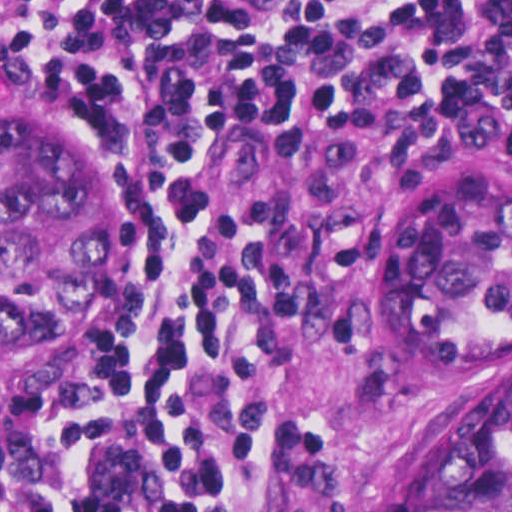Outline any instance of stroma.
<instances>
[{"label": "stroma", "instance_id": "stroma-1", "mask_svg": "<svg viewBox=\"0 0 512 512\" xmlns=\"http://www.w3.org/2000/svg\"><path fill=\"white\" fill-rule=\"evenodd\" d=\"M0 115L63 124L102 158L127 209V301L95 341L0 388L1 477L31 457L71 388L153 339L178 235L167 216L132 205L140 162L113 124L59 93L2 81ZM479 167L512 177V145L434 144L412 110L330 117L251 148L237 192L256 196L298 277V297L247 339L256 432L245 496L258 512H404L426 428L489 362L438 363L394 336V246L419 202Z\"/></svg>", "mask_w": 512, "mask_h": 512}]
</instances>
